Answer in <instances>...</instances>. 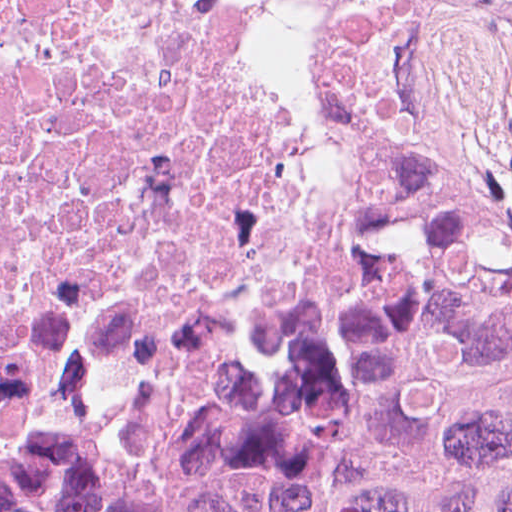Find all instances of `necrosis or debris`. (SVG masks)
Listing matches in <instances>:
<instances>
[{
  "instance_id": "obj_1",
  "label": "necrosis or debris",
  "mask_w": 512,
  "mask_h": 512,
  "mask_svg": "<svg viewBox=\"0 0 512 512\" xmlns=\"http://www.w3.org/2000/svg\"><path fill=\"white\" fill-rule=\"evenodd\" d=\"M428 162L512 228V0H0V464L189 473Z\"/></svg>"
}]
</instances>
